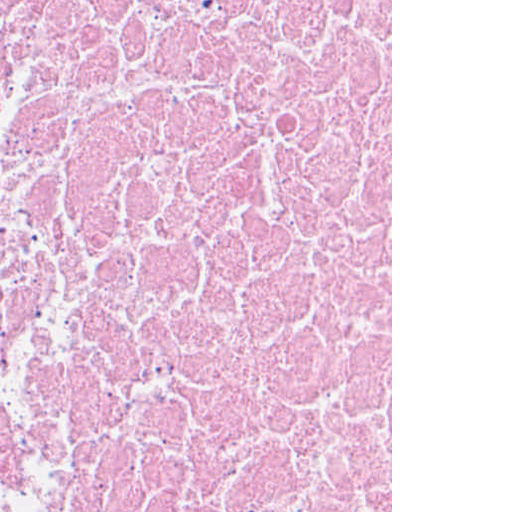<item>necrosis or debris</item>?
<instances>
[{"label":"necrosis or debris","instance_id":"1","mask_svg":"<svg viewBox=\"0 0 512 512\" xmlns=\"http://www.w3.org/2000/svg\"><path fill=\"white\" fill-rule=\"evenodd\" d=\"M0 512H391V0H0Z\"/></svg>","mask_w":512,"mask_h":512}]
</instances>
